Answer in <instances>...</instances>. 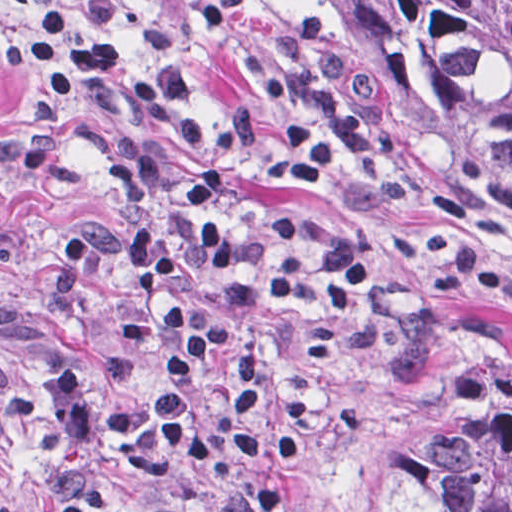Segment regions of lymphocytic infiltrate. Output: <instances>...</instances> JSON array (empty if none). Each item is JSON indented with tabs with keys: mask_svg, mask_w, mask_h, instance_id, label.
I'll return each instance as SVG.
<instances>
[{
	"mask_svg": "<svg viewBox=\"0 0 512 512\" xmlns=\"http://www.w3.org/2000/svg\"><path fill=\"white\" fill-rule=\"evenodd\" d=\"M10 92L0 112L29 126L24 161L57 188L105 173L120 204L129 287L120 341L148 345L141 305L158 294L162 374L100 406L79 372L42 380L73 447L110 468L73 487L61 512H117L138 490L237 464L277 512L301 499L286 473L317 453L328 421L358 432L374 406L327 387L291 385L285 357L322 363L351 345L384 351L397 317L383 292L378 237L302 210L255 212L259 181L293 188L333 175L367 139V116L343 87L342 34L312 5L277 28L261 59V113L245 102L209 127L194 75L133 56L126 9L45 3L3 43Z\"/></svg>",
	"mask_w": 512,
	"mask_h": 512,
	"instance_id": "1",
	"label": "lymphocytic infiltrate"
}]
</instances>
